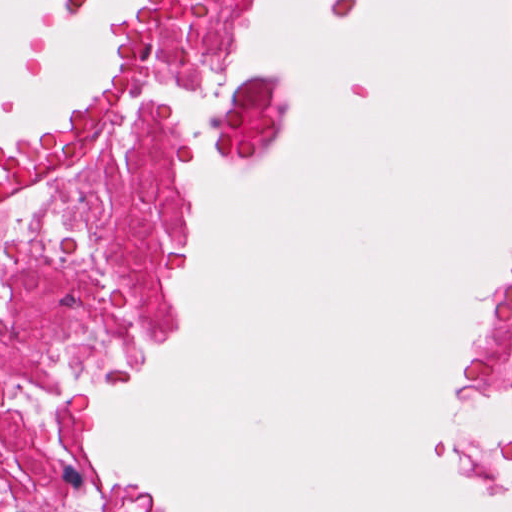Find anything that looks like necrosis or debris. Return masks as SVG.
<instances>
[{"mask_svg": "<svg viewBox=\"0 0 512 512\" xmlns=\"http://www.w3.org/2000/svg\"><path fill=\"white\" fill-rule=\"evenodd\" d=\"M222 31L223 0H144L123 77L0 159V512H89L75 486L89 391L154 316L168 209L153 138L170 124L241 143L256 124L214 116L197 86ZM482 374L512 403V288Z\"/></svg>", "mask_w": 512, "mask_h": 512, "instance_id": "obj_1", "label": "necrosis or debris"}]
</instances>
